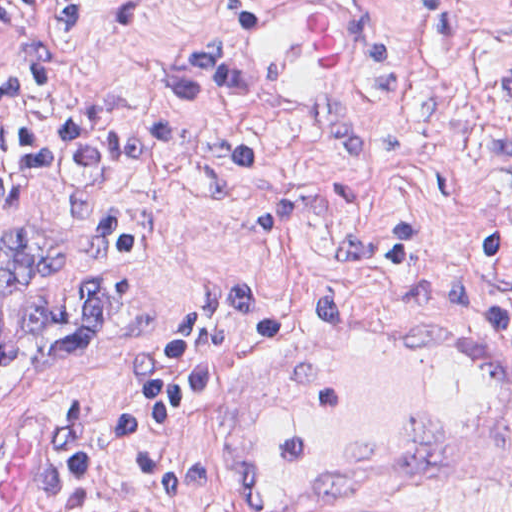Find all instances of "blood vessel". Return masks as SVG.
<instances>
[{"mask_svg": "<svg viewBox=\"0 0 512 512\" xmlns=\"http://www.w3.org/2000/svg\"><path fill=\"white\" fill-rule=\"evenodd\" d=\"M233 42L245 80L281 109L335 103L363 74L366 38L331 0H266ZM453 324L326 311L261 350L234 512L396 511L511 464L512 351Z\"/></svg>", "mask_w": 512, "mask_h": 512, "instance_id": "1", "label": "blood vessel"}]
</instances>
